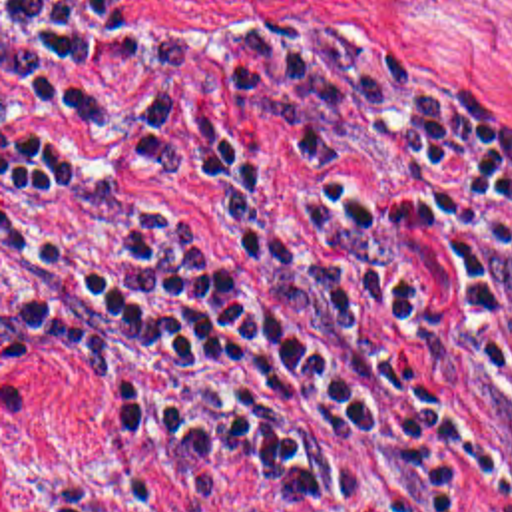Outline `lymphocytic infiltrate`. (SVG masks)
<instances>
[{
  "label": "lymphocytic infiltrate",
  "mask_w": 512,
  "mask_h": 512,
  "mask_svg": "<svg viewBox=\"0 0 512 512\" xmlns=\"http://www.w3.org/2000/svg\"><path fill=\"white\" fill-rule=\"evenodd\" d=\"M2 310L271 512H512V127L360 29L2 0Z\"/></svg>",
  "instance_id": "obj_1"
}]
</instances>
